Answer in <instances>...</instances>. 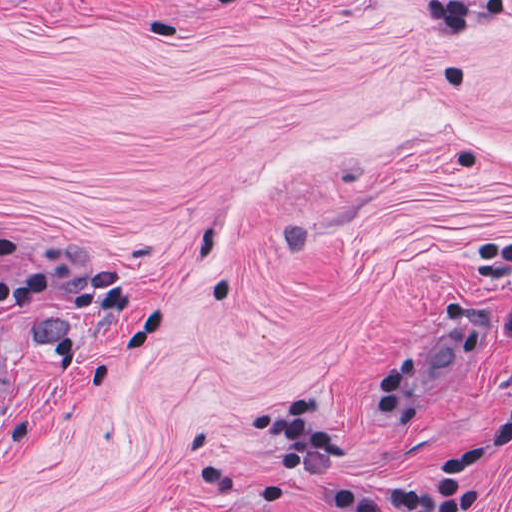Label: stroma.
<instances>
[{"label": "stroma", "instance_id": "1", "mask_svg": "<svg viewBox=\"0 0 512 512\" xmlns=\"http://www.w3.org/2000/svg\"><path fill=\"white\" fill-rule=\"evenodd\" d=\"M498 236L512 0H0V512H339L292 396L428 478L511 406Z\"/></svg>", "mask_w": 512, "mask_h": 512}]
</instances>
